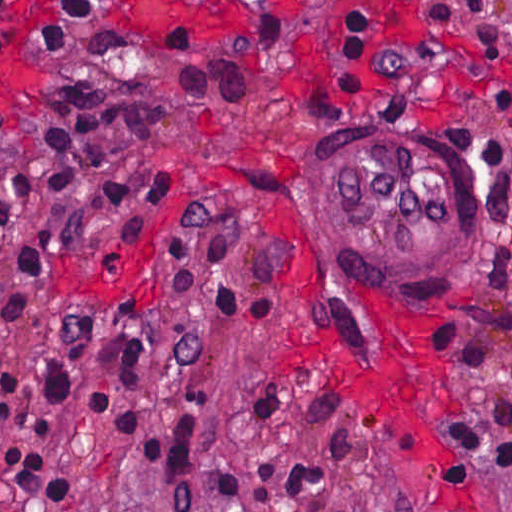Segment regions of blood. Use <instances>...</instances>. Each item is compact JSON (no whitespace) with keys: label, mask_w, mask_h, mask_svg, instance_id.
<instances>
[{"label":"blood","mask_w":512,"mask_h":512,"mask_svg":"<svg viewBox=\"0 0 512 512\" xmlns=\"http://www.w3.org/2000/svg\"><path fill=\"white\" fill-rule=\"evenodd\" d=\"M22 87V75L0 73V103ZM391 365L359 375L339 336L319 333L278 347L280 368L320 374L345 394L359 421L400 449L408 462H429V388L416 329L386 334Z\"/></svg>","instance_id":"1"}]
</instances>
